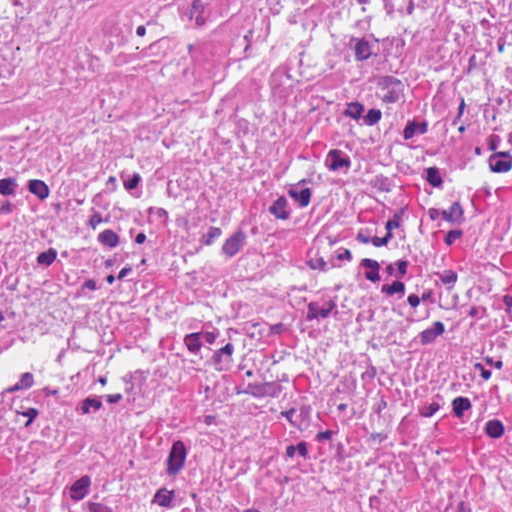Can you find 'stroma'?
<instances>
[{"label":"stroma","mask_w":512,"mask_h":512,"mask_svg":"<svg viewBox=\"0 0 512 512\" xmlns=\"http://www.w3.org/2000/svg\"><path fill=\"white\" fill-rule=\"evenodd\" d=\"M197 494H159L139 505L173 501ZM0 512H1V0H0Z\"/></svg>","instance_id":"stroma-1"}]
</instances>
